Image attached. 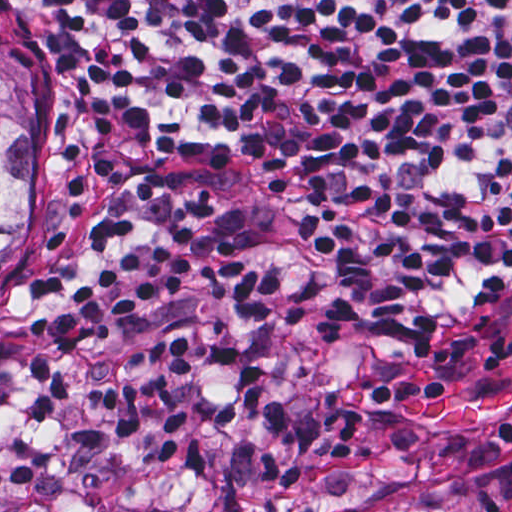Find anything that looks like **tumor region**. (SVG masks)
Segmentation results:
<instances>
[{"label":"tumor region","instance_id":"1","mask_svg":"<svg viewBox=\"0 0 512 512\" xmlns=\"http://www.w3.org/2000/svg\"><path fill=\"white\" fill-rule=\"evenodd\" d=\"M34 225V85L0 44V280Z\"/></svg>","mask_w":512,"mask_h":512}]
</instances>
